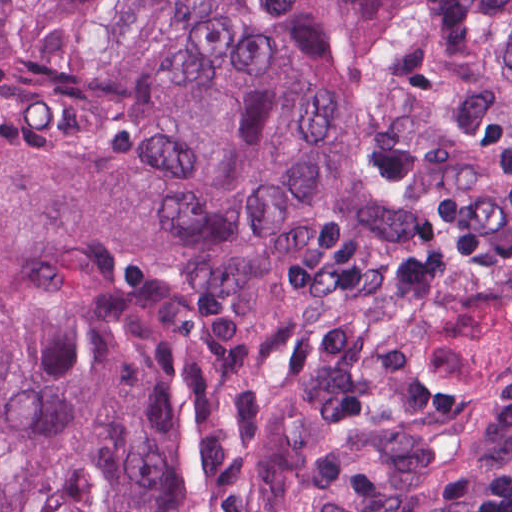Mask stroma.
<instances>
[{
    "label": "stroma",
    "mask_w": 512,
    "mask_h": 512,
    "mask_svg": "<svg viewBox=\"0 0 512 512\" xmlns=\"http://www.w3.org/2000/svg\"><path fill=\"white\" fill-rule=\"evenodd\" d=\"M512 338L460 363L421 402L387 426L343 512H394L442 466H512V389L499 371Z\"/></svg>",
    "instance_id": "obj_1"
}]
</instances>
